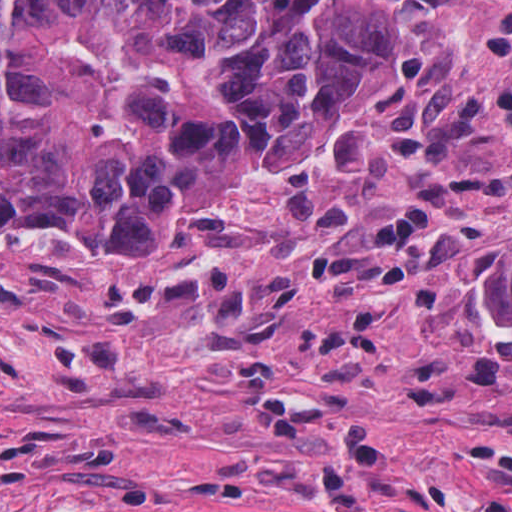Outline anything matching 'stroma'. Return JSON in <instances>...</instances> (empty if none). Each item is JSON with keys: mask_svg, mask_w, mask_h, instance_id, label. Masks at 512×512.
<instances>
[{"mask_svg": "<svg viewBox=\"0 0 512 512\" xmlns=\"http://www.w3.org/2000/svg\"><path fill=\"white\" fill-rule=\"evenodd\" d=\"M365 1L386 93L201 256L0 240V512H512V1Z\"/></svg>", "mask_w": 512, "mask_h": 512, "instance_id": "obj_1", "label": "stroma"}]
</instances>
